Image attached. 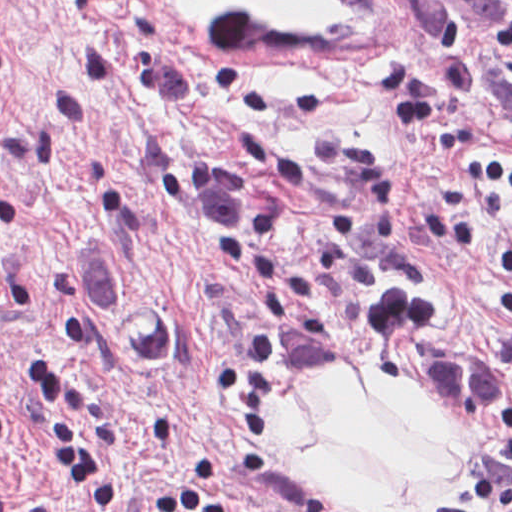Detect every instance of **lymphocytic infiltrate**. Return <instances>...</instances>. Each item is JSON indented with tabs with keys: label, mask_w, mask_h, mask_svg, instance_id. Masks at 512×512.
<instances>
[{
	"label": "lymphocytic infiltrate",
	"mask_w": 512,
	"mask_h": 512,
	"mask_svg": "<svg viewBox=\"0 0 512 512\" xmlns=\"http://www.w3.org/2000/svg\"><path fill=\"white\" fill-rule=\"evenodd\" d=\"M27 369L28 393L56 464L103 508L116 509L122 504L121 474L94 444L89 407L68 369L50 356H28ZM0 512H13L1 481Z\"/></svg>",
	"instance_id": "1"
}]
</instances>
